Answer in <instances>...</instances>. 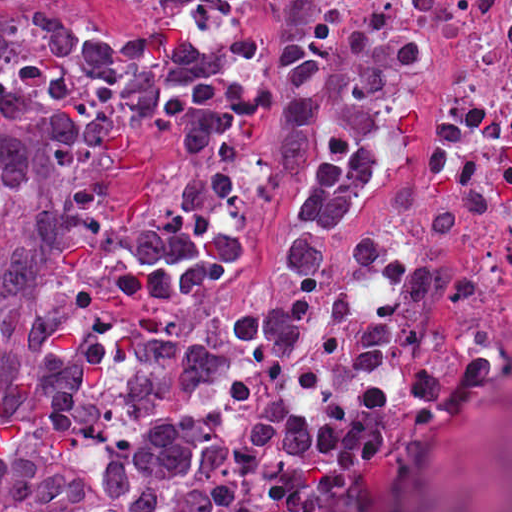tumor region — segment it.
I'll return each mask as SVG.
<instances>
[{
	"mask_svg": "<svg viewBox=\"0 0 512 512\" xmlns=\"http://www.w3.org/2000/svg\"><path fill=\"white\" fill-rule=\"evenodd\" d=\"M197 40L169 19L94 26L47 2L0 26V217L22 178L88 157L124 110L194 77Z\"/></svg>",
	"mask_w": 512,
	"mask_h": 512,
	"instance_id": "1",
	"label": "tumor region"
}]
</instances>
